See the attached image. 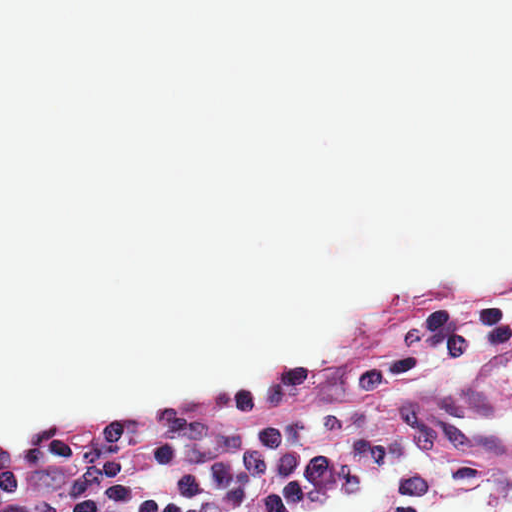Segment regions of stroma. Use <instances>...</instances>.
I'll list each match as a JSON object with an SVG mask.
<instances>
[{"instance_id": "35a3bbf8", "label": "stroma", "mask_w": 512, "mask_h": 512, "mask_svg": "<svg viewBox=\"0 0 512 512\" xmlns=\"http://www.w3.org/2000/svg\"><path fill=\"white\" fill-rule=\"evenodd\" d=\"M512 279V256L416 275H380L354 294L345 308L295 331L275 352L226 369H190L178 376L146 378L129 390L35 411L0 424V448L35 426L84 418L281 370L312 349L345 340L383 299L411 287H471ZM512 399V347L476 356L446 374L410 386L384 408L382 423L414 443V464L379 471L316 500L300 512H361L370 502H391L436 511H512V459H487L439 450L402 423L399 405Z\"/></svg>"}]
</instances>
